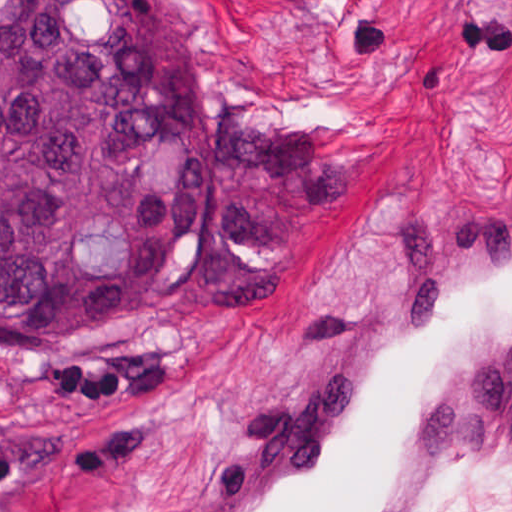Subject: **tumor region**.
Listing matches in <instances>:
<instances>
[{
  "label": "tumor region",
  "mask_w": 512,
  "mask_h": 512,
  "mask_svg": "<svg viewBox=\"0 0 512 512\" xmlns=\"http://www.w3.org/2000/svg\"><path fill=\"white\" fill-rule=\"evenodd\" d=\"M341 194L322 127L206 99L179 0H0V346L270 304Z\"/></svg>",
  "instance_id": "e687c5a6"
}]
</instances>
